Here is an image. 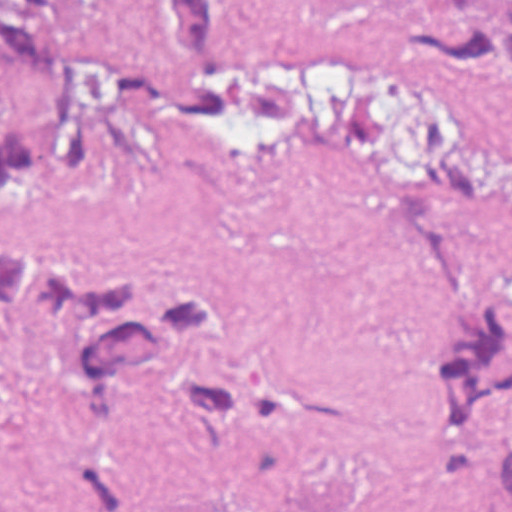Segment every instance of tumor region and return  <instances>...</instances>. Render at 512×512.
<instances>
[{
    "instance_id": "e687c5a6",
    "label": "tumor region",
    "mask_w": 512,
    "mask_h": 512,
    "mask_svg": "<svg viewBox=\"0 0 512 512\" xmlns=\"http://www.w3.org/2000/svg\"><path fill=\"white\" fill-rule=\"evenodd\" d=\"M149 27L158 42L147 53L48 38V0H0V189L32 184L45 167L87 170L165 123L300 137L421 184L488 182L486 150L470 133L373 81L283 53L236 0H151ZM393 39L417 77L512 78V0L411 5ZM399 243L426 321L430 431L475 493L512 501V449L494 429L512 406V255L443 203L402 206ZM35 327L65 329L70 341L56 420L73 512H181L134 456L115 403L125 388L250 449L317 430L315 401L252 362L249 312L223 285L59 248L1 253L0 350Z\"/></svg>"
}]
</instances>
